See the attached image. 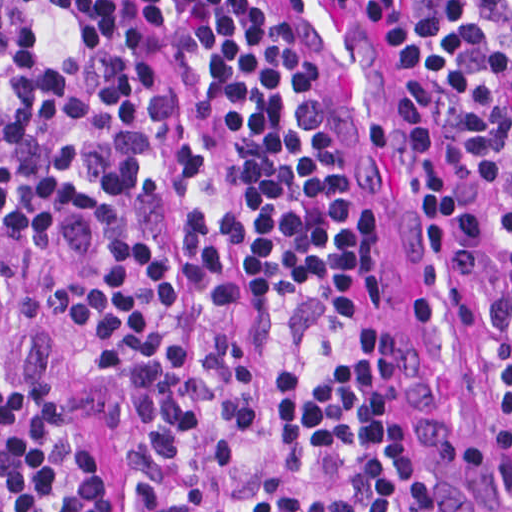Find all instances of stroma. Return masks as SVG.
Segmentation results:
<instances>
[{
  "mask_svg": "<svg viewBox=\"0 0 512 512\" xmlns=\"http://www.w3.org/2000/svg\"><path fill=\"white\" fill-rule=\"evenodd\" d=\"M281 36H282V34H281ZM282 39L295 58L302 96H303V99H304V101H305L314 121H315L319 145L321 147V150L323 152L325 160H326L327 164L339 175L335 155H334V152H333V149H332V146H331V143H330L327 131H326L321 107H320V104H319L314 92L311 89L308 73L304 69L302 64L299 62L297 57L294 55V53L292 52L291 48L289 47L288 43L286 42V40L283 36H282ZM385 43L391 49L393 56L395 58V61L398 65V67L400 68V70L402 71V66H401L393 48L386 41H385ZM364 338L366 339L376 361L393 377V379H394V381L404 399L405 408L407 411V415H408L410 424L423 445L420 431H419V428H418V425H417V422H416V419H415V416H414V413H413V410H412V407H411V404H410V401H409V398H408V395H407V392L405 389V383H404V380L402 377V373H401L393 346H392L391 341L387 335L381 305L378 300V297L375 292L373 284H372V299H371V304H370ZM423 447H424V445H423ZM432 467H433L436 486L438 488L439 494H440L442 502H443L441 490L439 487V483L437 480V476H436L433 464H432ZM443 504H444V502H443ZM444 508H445V506H444ZM445 512H446V510H445Z\"/></svg>",
  "mask_w": 512,
  "mask_h": 512,
  "instance_id": "obj_1",
  "label": "stroma"
}]
</instances>
